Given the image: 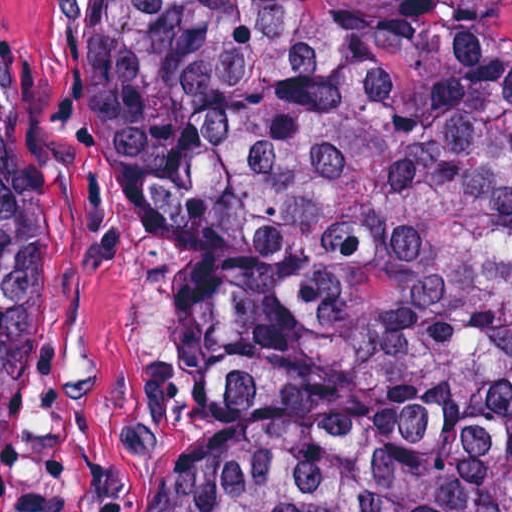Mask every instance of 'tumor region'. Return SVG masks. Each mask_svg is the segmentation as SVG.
<instances>
[{"label": "tumor region", "instance_id": "1", "mask_svg": "<svg viewBox=\"0 0 512 512\" xmlns=\"http://www.w3.org/2000/svg\"><path fill=\"white\" fill-rule=\"evenodd\" d=\"M79 123L181 251L207 436L140 512H512V23L107 1ZM46 76L0 24V512H38Z\"/></svg>", "mask_w": 512, "mask_h": 512}]
</instances>
